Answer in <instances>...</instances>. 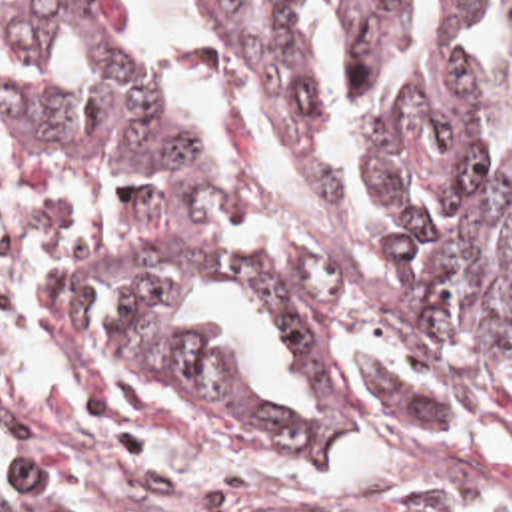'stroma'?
Wrapping results in <instances>:
<instances>
[{
	"mask_svg": "<svg viewBox=\"0 0 512 512\" xmlns=\"http://www.w3.org/2000/svg\"><path fill=\"white\" fill-rule=\"evenodd\" d=\"M231 64L267 158L253 176L269 186L285 176L275 138ZM159 216L137 192L0 182V414L167 495L235 511L512 512V434H399L295 452L273 420L67 334V276L145 248Z\"/></svg>",
	"mask_w": 512,
	"mask_h": 512,
	"instance_id": "1",
	"label": "stroma"
}]
</instances>
